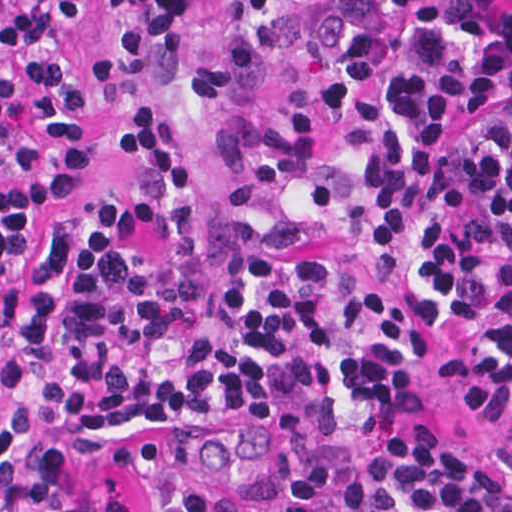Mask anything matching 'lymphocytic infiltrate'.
<instances>
[{"label": "lymphocytic infiltrate", "mask_w": 512, "mask_h": 512, "mask_svg": "<svg viewBox=\"0 0 512 512\" xmlns=\"http://www.w3.org/2000/svg\"><path fill=\"white\" fill-rule=\"evenodd\" d=\"M194 0H114L181 21ZM276 0H238L261 16ZM314 101L243 121L210 262L196 174L162 121L127 123L143 215L94 197L29 233L87 169L62 151L0 185V487L25 496L162 424L255 414L281 481L317 484L326 432L393 414L426 344L460 339L485 453L456 431L389 456L350 512H512V0H338ZM83 0H0V184L38 128L75 127L129 90L227 89L273 43L187 63L128 40L81 65ZM149 512H244L185 471L146 480ZM63 512H121L101 500Z\"/></svg>", "instance_id": "1"}]
</instances>
